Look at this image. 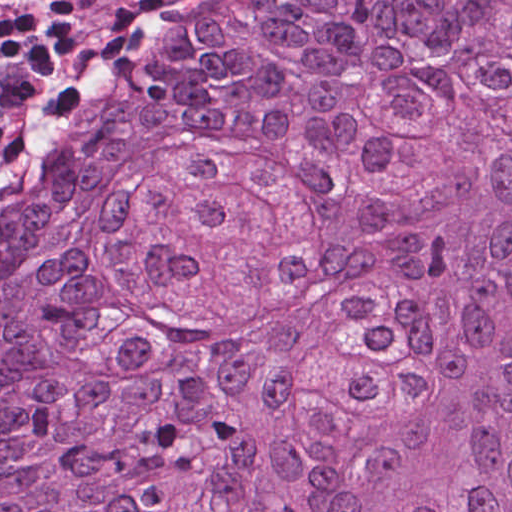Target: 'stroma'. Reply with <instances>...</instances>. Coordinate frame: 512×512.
<instances>
[{
  "label": "stroma",
  "instance_id": "stroma-1",
  "mask_svg": "<svg viewBox=\"0 0 512 512\" xmlns=\"http://www.w3.org/2000/svg\"><path fill=\"white\" fill-rule=\"evenodd\" d=\"M195 0H155L100 46L83 64L78 75L102 72L118 59L146 32L156 28L162 33Z\"/></svg>",
  "mask_w": 512,
  "mask_h": 512
}]
</instances>
